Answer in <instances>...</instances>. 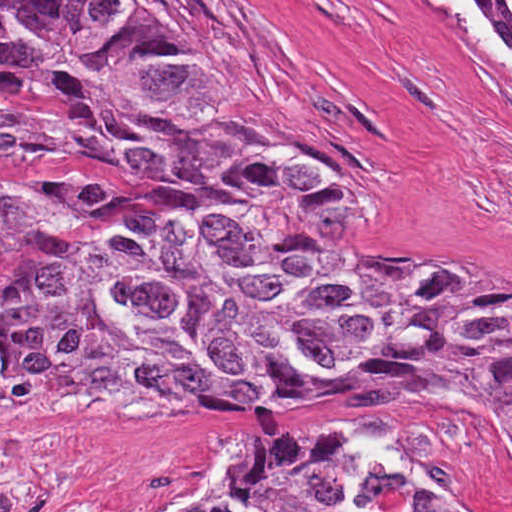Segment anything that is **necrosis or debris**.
<instances>
[{"label": "necrosis or debris", "instance_id": "4bbe7bcc", "mask_svg": "<svg viewBox=\"0 0 512 512\" xmlns=\"http://www.w3.org/2000/svg\"><path fill=\"white\" fill-rule=\"evenodd\" d=\"M52 230H86L116 209L98 183L43 158L0 153V201ZM0 347V512L47 511V436L28 419Z\"/></svg>", "mask_w": 512, "mask_h": 512}]
</instances>
